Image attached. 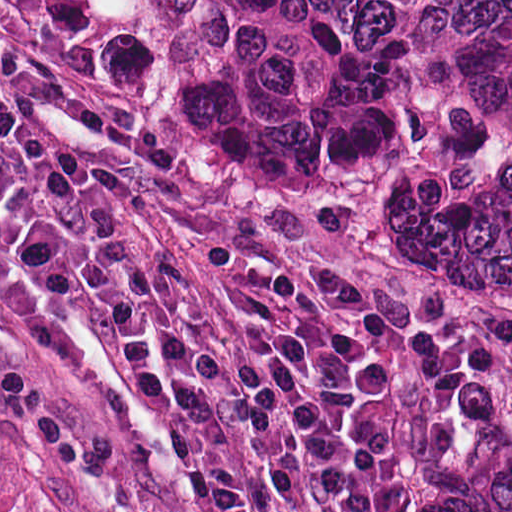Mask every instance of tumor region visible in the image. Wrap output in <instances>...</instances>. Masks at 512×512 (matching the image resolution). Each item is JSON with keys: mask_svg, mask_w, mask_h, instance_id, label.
<instances>
[{"mask_svg": "<svg viewBox=\"0 0 512 512\" xmlns=\"http://www.w3.org/2000/svg\"><path fill=\"white\" fill-rule=\"evenodd\" d=\"M0 512H30L0 469ZM405 512H512V401H457L418 463Z\"/></svg>", "mask_w": 512, "mask_h": 512, "instance_id": "1", "label": "tumor region"}]
</instances>
